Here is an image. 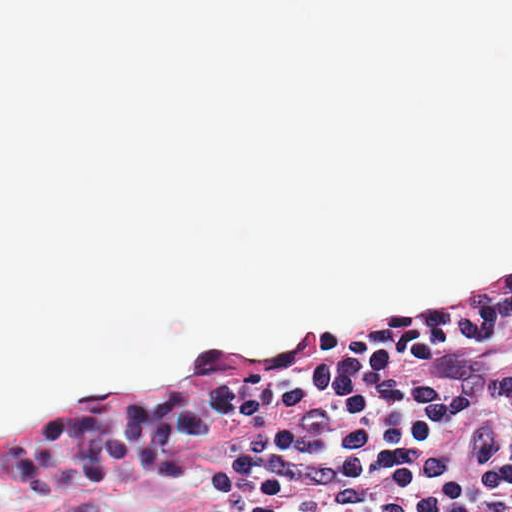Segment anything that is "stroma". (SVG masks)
<instances>
[{
  "instance_id": "35a3bbf8",
  "label": "stroma",
  "mask_w": 512,
  "mask_h": 512,
  "mask_svg": "<svg viewBox=\"0 0 512 512\" xmlns=\"http://www.w3.org/2000/svg\"><path fill=\"white\" fill-rule=\"evenodd\" d=\"M506 275H512V258L447 273L416 286L402 300L380 313L341 311L255 351H270L298 334L334 338L346 331L382 328L413 318L422 298L440 296L470 283ZM226 503L224 486L210 455L180 471H142L126 478L118 491L48 495L21 512H211Z\"/></svg>"
}]
</instances>
